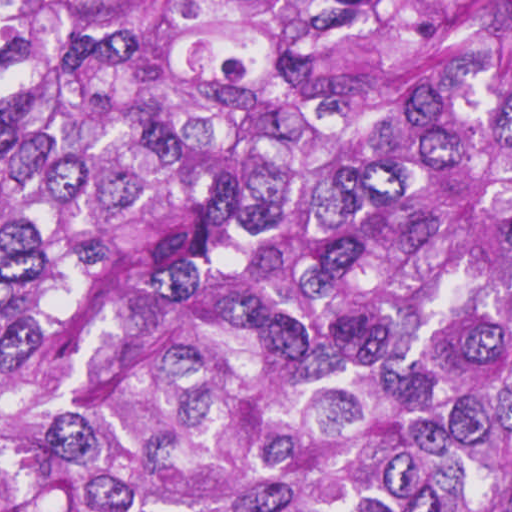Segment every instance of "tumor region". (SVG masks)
<instances>
[{"instance_id": "obj_1", "label": "tumor region", "mask_w": 512, "mask_h": 512, "mask_svg": "<svg viewBox=\"0 0 512 512\" xmlns=\"http://www.w3.org/2000/svg\"><path fill=\"white\" fill-rule=\"evenodd\" d=\"M0 512H512V0H0Z\"/></svg>"}]
</instances>
